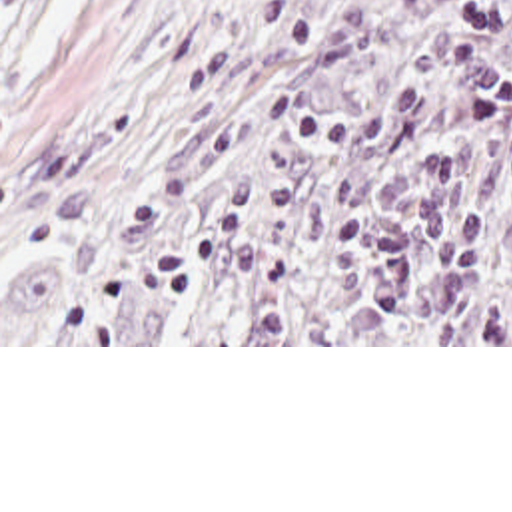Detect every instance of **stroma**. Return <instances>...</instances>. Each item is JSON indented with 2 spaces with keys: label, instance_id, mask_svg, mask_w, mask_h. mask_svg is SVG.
Listing matches in <instances>:
<instances>
[{
  "label": "stroma",
  "instance_id": "1",
  "mask_svg": "<svg viewBox=\"0 0 512 512\" xmlns=\"http://www.w3.org/2000/svg\"><path fill=\"white\" fill-rule=\"evenodd\" d=\"M290 0H0V347H512L437 343H2L34 253L106 237L236 44Z\"/></svg>",
  "mask_w": 512,
  "mask_h": 512
}]
</instances>
